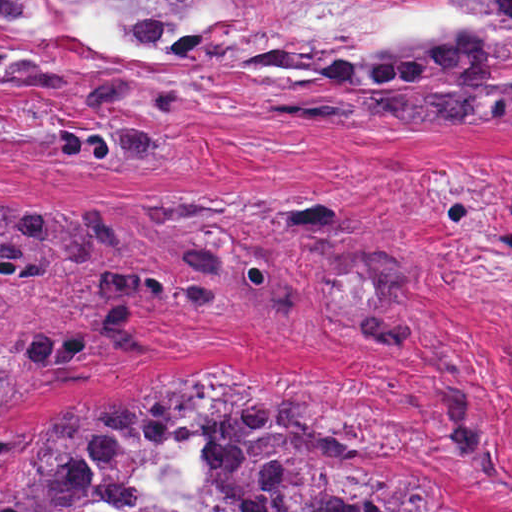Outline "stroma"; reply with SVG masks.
Segmentation results:
<instances>
[{"label": "stroma", "mask_w": 512, "mask_h": 512, "mask_svg": "<svg viewBox=\"0 0 512 512\" xmlns=\"http://www.w3.org/2000/svg\"><path fill=\"white\" fill-rule=\"evenodd\" d=\"M264 2H253L174 100L213 50L138 114L121 117L160 145L157 172L50 154L62 130L102 122L88 102L0 94V188L146 212L220 194H322L394 223L439 279L430 310L473 356V414L509 471V501L472 487L430 357L335 325L293 292L244 316L170 312L148 326L146 353L44 387L10 430L78 404L85 414L148 387H187L224 355L297 389L335 442L426 485L443 509L512 512V106L234 118L214 89ZM299 5L350 40L455 35L470 11L466 0Z\"/></svg>", "instance_id": "35a3bbf8"}]
</instances>
